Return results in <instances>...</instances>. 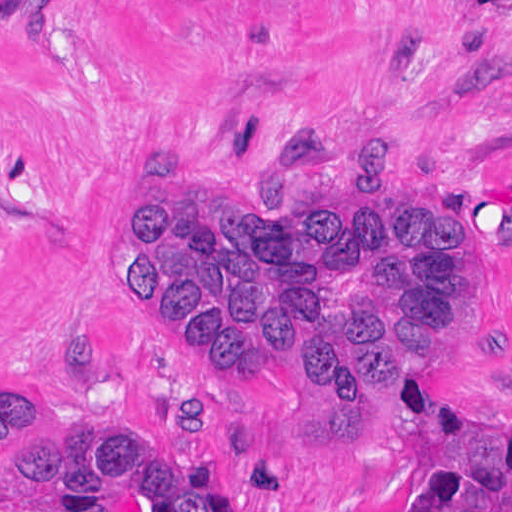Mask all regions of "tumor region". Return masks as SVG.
<instances>
[{"label": "tumor region", "mask_w": 512, "mask_h": 512, "mask_svg": "<svg viewBox=\"0 0 512 512\" xmlns=\"http://www.w3.org/2000/svg\"><path fill=\"white\" fill-rule=\"evenodd\" d=\"M267 149L336 152L327 127L283 126ZM351 153L396 155L383 134ZM473 221L364 208L309 219L235 201L151 202L125 271L131 302L212 366L281 356L307 391L363 407L446 362L469 316ZM423 472L419 512H512V427ZM218 512L209 485L117 431L56 433L28 401L0 400V512Z\"/></svg>", "instance_id": "tumor-region-1"}]
</instances>
